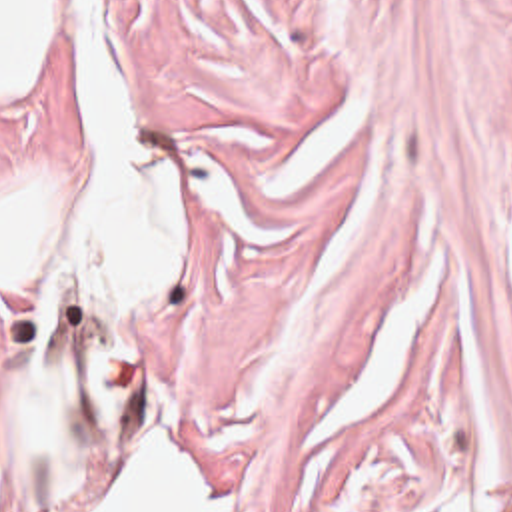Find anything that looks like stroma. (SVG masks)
Segmentation results:
<instances>
[{
	"label": "stroma",
	"instance_id": "stroma-1",
	"mask_svg": "<svg viewBox=\"0 0 512 512\" xmlns=\"http://www.w3.org/2000/svg\"><path fill=\"white\" fill-rule=\"evenodd\" d=\"M0 92V178L78 142L80 16ZM176 154L172 280L98 350L110 446L40 512L120 502L158 438L214 512H443L463 450L512 512V0H102ZM427 266L405 376L298 456Z\"/></svg>",
	"mask_w": 512,
	"mask_h": 512
}]
</instances>
